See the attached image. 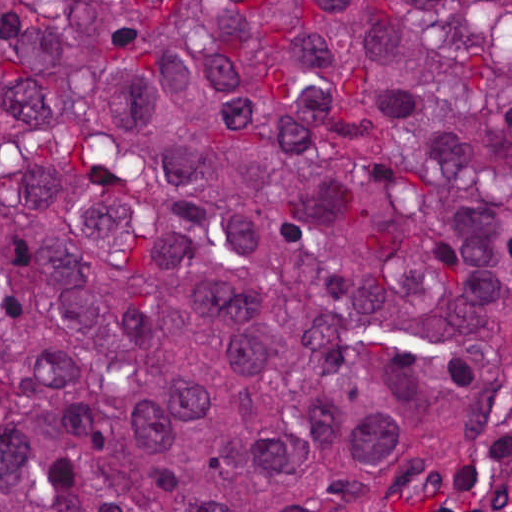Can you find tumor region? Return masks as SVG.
<instances>
[{
  "instance_id": "e687c5a6",
  "label": "tumor region",
  "mask_w": 512,
  "mask_h": 512,
  "mask_svg": "<svg viewBox=\"0 0 512 512\" xmlns=\"http://www.w3.org/2000/svg\"><path fill=\"white\" fill-rule=\"evenodd\" d=\"M512 361V0H1V512H388Z\"/></svg>"
}]
</instances>
